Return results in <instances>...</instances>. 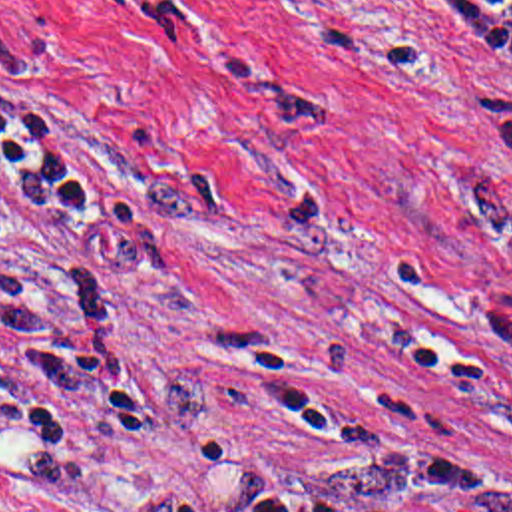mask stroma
Returning a JSON list of instances; mask_svg holds the SVG:
<instances>
[{
	"mask_svg": "<svg viewBox=\"0 0 512 512\" xmlns=\"http://www.w3.org/2000/svg\"><path fill=\"white\" fill-rule=\"evenodd\" d=\"M457 0H0V512H512V81Z\"/></svg>",
	"mask_w": 512,
	"mask_h": 512,
	"instance_id": "1",
	"label": "stroma"
}]
</instances>
